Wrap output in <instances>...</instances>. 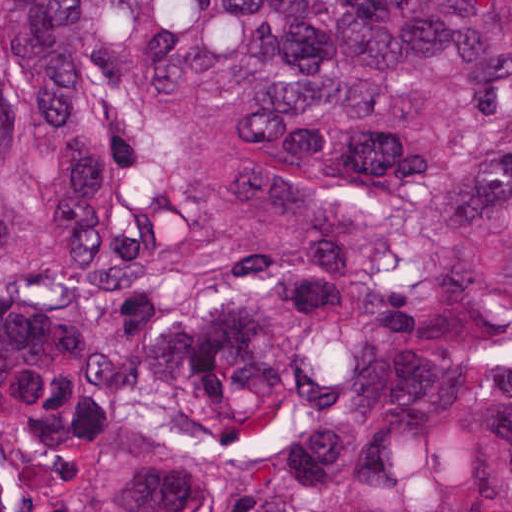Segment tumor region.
<instances>
[{
    "label": "tumor region",
    "mask_w": 512,
    "mask_h": 512,
    "mask_svg": "<svg viewBox=\"0 0 512 512\" xmlns=\"http://www.w3.org/2000/svg\"><path fill=\"white\" fill-rule=\"evenodd\" d=\"M0 512H512V0H0Z\"/></svg>",
    "instance_id": "tumor-region-1"
}]
</instances>
